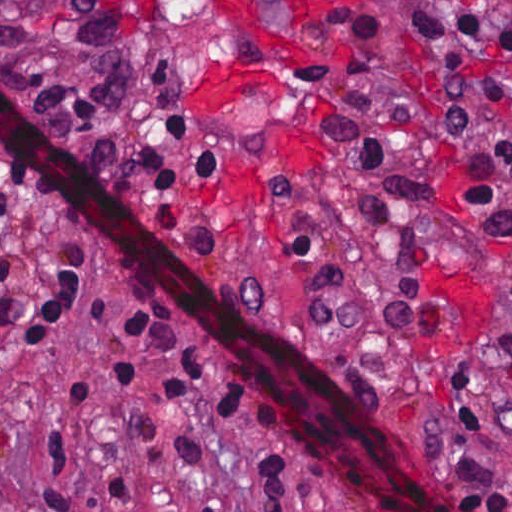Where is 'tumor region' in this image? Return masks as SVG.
<instances>
[{
    "label": "tumor region",
    "mask_w": 512,
    "mask_h": 512,
    "mask_svg": "<svg viewBox=\"0 0 512 512\" xmlns=\"http://www.w3.org/2000/svg\"><path fill=\"white\" fill-rule=\"evenodd\" d=\"M0 85L111 185L140 110L115 0H0ZM133 131V135H132Z\"/></svg>",
    "instance_id": "tumor-region-1"
}]
</instances>
